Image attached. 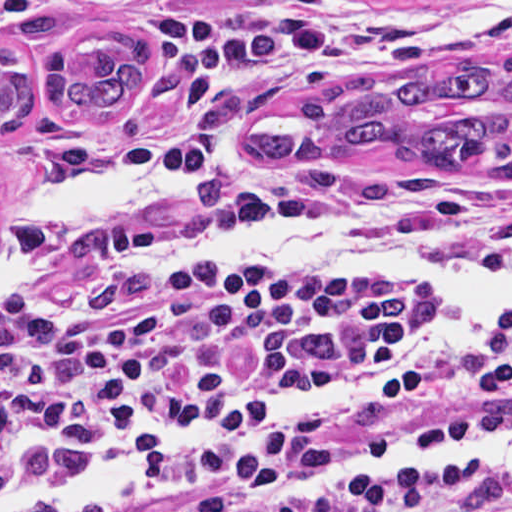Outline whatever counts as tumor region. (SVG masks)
I'll return each mask as SVG.
<instances>
[{
	"label": "tumor region",
	"mask_w": 512,
	"mask_h": 512,
	"mask_svg": "<svg viewBox=\"0 0 512 512\" xmlns=\"http://www.w3.org/2000/svg\"><path fill=\"white\" fill-rule=\"evenodd\" d=\"M143 73L139 39L92 33L70 56L62 50L51 55L49 101L71 118L107 119L139 89ZM33 104L34 76L26 59L0 45V132L17 131ZM238 155L263 170L372 156L512 184V62L473 56L331 78L267 108L243 132Z\"/></svg>",
	"instance_id": "1"
}]
</instances>
